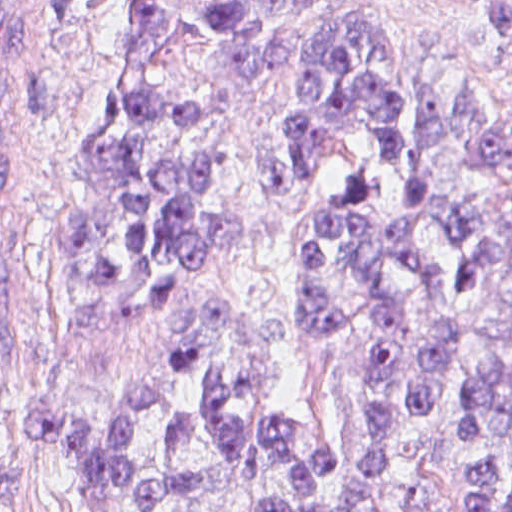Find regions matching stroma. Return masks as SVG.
I'll return each instance as SVG.
<instances>
[{"instance_id": "1", "label": "stroma", "mask_w": 512, "mask_h": 512, "mask_svg": "<svg viewBox=\"0 0 512 512\" xmlns=\"http://www.w3.org/2000/svg\"><path fill=\"white\" fill-rule=\"evenodd\" d=\"M185 1H377L395 70L433 67L491 104L512 105V26L485 33L465 2L512 0H0L1 213L48 256V279L6 294V375L20 417L10 512H87L33 408H89L111 400L193 342L202 360L159 374L165 401L135 435L139 447L149 448L172 412L185 410L189 443L163 472L196 470L202 486L150 512H263L268 498L293 488L276 461L238 462L221 447L201 405L214 368L252 435L269 417H287L296 424L300 456L318 435L349 444L346 466L326 477L319 492L344 493L366 454L368 305L353 284L335 280L336 299L352 317L340 339L322 346L303 335L301 296L308 227L354 172L366 133L361 127L349 134L314 179L272 206L263 164L280 152L290 84L277 74L262 87L246 88L214 74L219 50L201 3L179 11L175 34L149 61V79L164 93H197L201 111L191 129L211 150L207 202L215 214L235 220L234 231L215 238L209 260L173 299L70 279L62 261L64 221L93 103L121 61ZM425 314L456 332L457 366L442 400L402 430L355 512H397L384 501L406 484L434 488L435 512H462L467 469L512 462V412L479 440L458 438V408L476 369L475 336L452 309ZM180 324L179 338H170Z\"/></svg>"}]
</instances>
